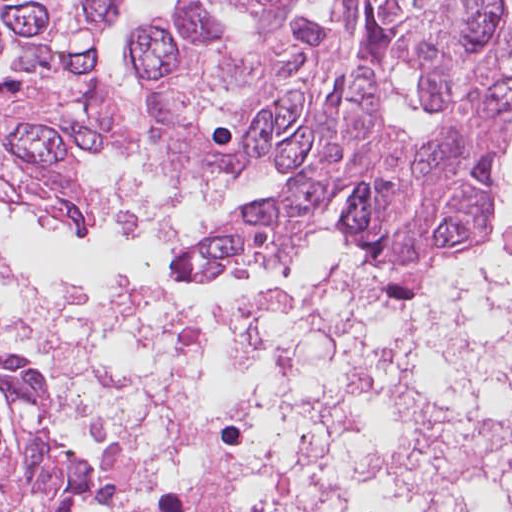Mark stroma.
Segmentation results:
<instances>
[{
    "label": "stroma",
    "instance_id": "35a3bbf8",
    "mask_svg": "<svg viewBox=\"0 0 512 512\" xmlns=\"http://www.w3.org/2000/svg\"><path fill=\"white\" fill-rule=\"evenodd\" d=\"M292 182L253 194L249 195L213 208H209L200 212L195 213L196 216L203 222V232L206 234L208 231H210L212 228H214L217 224H219L224 218L230 216L231 214L242 210L246 207H260L262 205H265L273 200H275L277 197H279L290 185ZM494 226H493V220L492 215L490 219V233L488 238L475 245H483L487 243L494 242ZM473 246V247H475ZM358 257L360 258L359 254ZM186 275H208V274H186Z\"/></svg>",
    "mask_w": 512,
    "mask_h": 512
}]
</instances>
